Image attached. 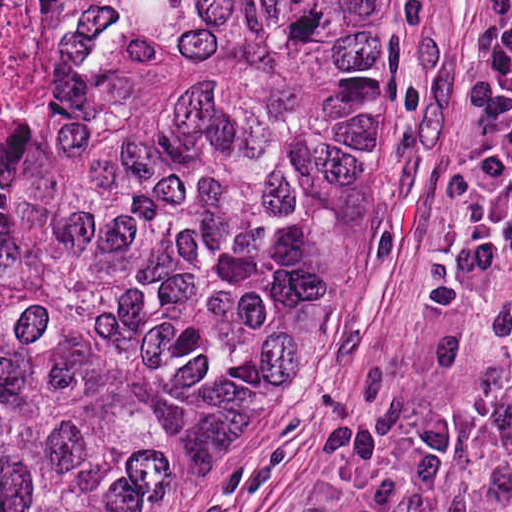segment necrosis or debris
Here are the masks:
<instances>
[{"label":"necrosis or debris","mask_w":512,"mask_h":512,"mask_svg":"<svg viewBox=\"0 0 512 512\" xmlns=\"http://www.w3.org/2000/svg\"><path fill=\"white\" fill-rule=\"evenodd\" d=\"M13 0H0V65L12 9Z\"/></svg>","instance_id":"obj_1"}]
</instances>
